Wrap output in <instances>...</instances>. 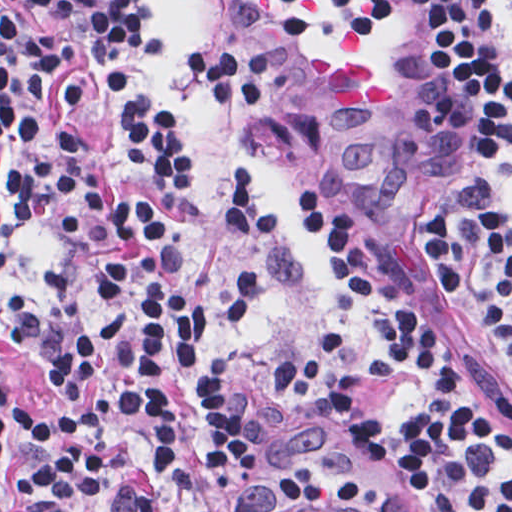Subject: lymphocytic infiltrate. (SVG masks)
<instances>
[{
	"label": "lymphocytic infiltrate",
	"instance_id": "f902f5d3",
	"mask_svg": "<svg viewBox=\"0 0 512 512\" xmlns=\"http://www.w3.org/2000/svg\"><path fill=\"white\" fill-rule=\"evenodd\" d=\"M59 20L27 24L0 7V231L52 226L68 285L0 282V512H214L263 452L244 428L228 347L253 327L277 281L282 218L259 171L223 192L235 281L219 313L198 304L181 244L142 190L104 181L88 158V108L117 106L134 160L163 193L183 174L174 117L134 82L145 26L137 0H30ZM255 25L321 29L415 21L438 50L454 114L451 180L393 273L362 248L337 201L282 183L357 287L370 351L338 316L298 350L271 357L289 392L346 420L436 512H512V424L454 368L435 283L459 287L512 361V219L503 200V50L485 0H249ZM215 102L268 104L273 92L216 43L196 41ZM416 374L420 399L398 425L357 399L376 377ZM300 512H324L277 476Z\"/></svg>",
	"mask_w": 512,
	"mask_h": 512
}]
</instances>
